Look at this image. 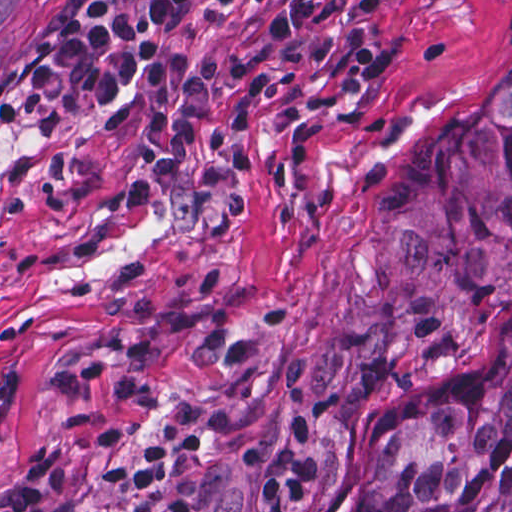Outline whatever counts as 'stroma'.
Wrapping results in <instances>:
<instances>
[{
    "mask_svg": "<svg viewBox=\"0 0 512 512\" xmlns=\"http://www.w3.org/2000/svg\"><path fill=\"white\" fill-rule=\"evenodd\" d=\"M63 0H0V89ZM272 0H195L168 59L243 33ZM379 86H265L234 160L240 213L170 233L139 147V88L58 118L0 93V484L65 472L56 512H264L235 454L302 408L342 512L366 444L500 365L512 307L451 354L347 383L336 310L379 169L492 96L512 65V0H361Z\"/></svg>",
    "mask_w": 512,
    "mask_h": 512,
    "instance_id": "obj_1",
    "label": "stroma"
}]
</instances>
